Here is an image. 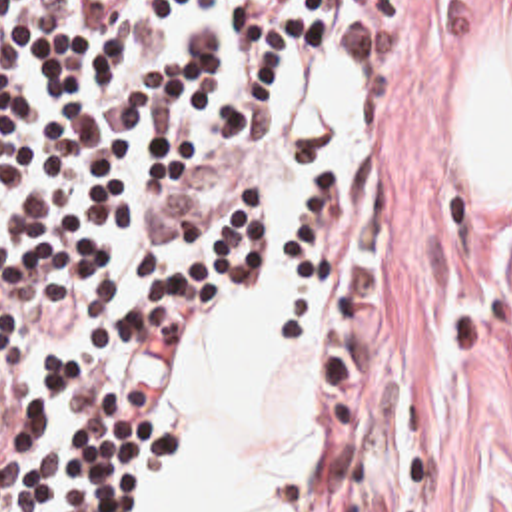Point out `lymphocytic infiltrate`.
I'll return each mask as SVG.
<instances>
[{
    "label": "lymphocytic infiltrate",
    "instance_id": "obj_1",
    "mask_svg": "<svg viewBox=\"0 0 512 512\" xmlns=\"http://www.w3.org/2000/svg\"><path fill=\"white\" fill-rule=\"evenodd\" d=\"M366 0H0V512H162V391L212 301L360 243L338 81ZM214 147L242 201L144 237Z\"/></svg>",
    "mask_w": 512,
    "mask_h": 512
}]
</instances>
